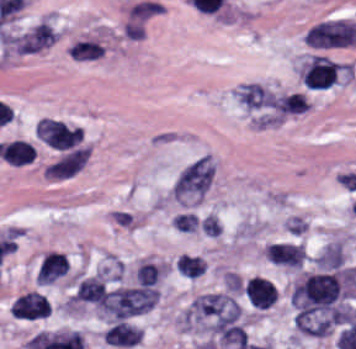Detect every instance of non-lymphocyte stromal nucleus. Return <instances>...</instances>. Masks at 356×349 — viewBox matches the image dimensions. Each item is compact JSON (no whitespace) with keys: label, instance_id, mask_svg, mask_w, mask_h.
Segmentation results:
<instances>
[{"label":"non-lymphocyte stromal nucleus","instance_id":"616ff342","mask_svg":"<svg viewBox=\"0 0 356 349\" xmlns=\"http://www.w3.org/2000/svg\"><path fill=\"white\" fill-rule=\"evenodd\" d=\"M305 257L301 245L271 244L266 250V258L278 266L300 268Z\"/></svg>","mask_w":356,"mask_h":349},{"label":"non-lymphocyte stromal nucleus","instance_id":"51effc4e","mask_svg":"<svg viewBox=\"0 0 356 349\" xmlns=\"http://www.w3.org/2000/svg\"><path fill=\"white\" fill-rule=\"evenodd\" d=\"M104 48L93 40H79L73 43L68 52L74 60H94L102 55Z\"/></svg>","mask_w":356,"mask_h":349},{"label":"non-lymphocyte stromal nucleus","instance_id":"9d01c50a","mask_svg":"<svg viewBox=\"0 0 356 349\" xmlns=\"http://www.w3.org/2000/svg\"><path fill=\"white\" fill-rule=\"evenodd\" d=\"M88 157L87 147H73L49 165V177L70 176L85 164Z\"/></svg>","mask_w":356,"mask_h":349},{"label":"non-lymphocyte stromal nucleus","instance_id":"81446118","mask_svg":"<svg viewBox=\"0 0 356 349\" xmlns=\"http://www.w3.org/2000/svg\"><path fill=\"white\" fill-rule=\"evenodd\" d=\"M356 39V22L344 19L325 20L312 26L304 35V42L316 47L353 44Z\"/></svg>","mask_w":356,"mask_h":349},{"label":"non-lymphocyte stromal nucleus","instance_id":"0ceb972a","mask_svg":"<svg viewBox=\"0 0 356 349\" xmlns=\"http://www.w3.org/2000/svg\"><path fill=\"white\" fill-rule=\"evenodd\" d=\"M309 101L304 93H291L274 98V109L282 114H303L306 112Z\"/></svg>","mask_w":356,"mask_h":349},{"label":"non-lymphocyte stromal nucleus","instance_id":"2ac0efb1","mask_svg":"<svg viewBox=\"0 0 356 349\" xmlns=\"http://www.w3.org/2000/svg\"><path fill=\"white\" fill-rule=\"evenodd\" d=\"M57 33L42 20L18 40V51L35 52L56 41Z\"/></svg>","mask_w":356,"mask_h":349},{"label":"non-lymphocyte stromal nucleus","instance_id":"bbfbcbc0","mask_svg":"<svg viewBox=\"0 0 356 349\" xmlns=\"http://www.w3.org/2000/svg\"><path fill=\"white\" fill-rule=\"evenodd\" d=\"M162 267L148 262H141L136 267L135 277L137 283L147 286L155 285L161 276Z\"/></svg>","mask_w":356,"mask_h":349},{"label":"non-lymphocyte stromal nucleus","instance_id":"3746e769","mask_svg":"<svg viewBox=\"0 0 356 349\" xmlns=\"http://www.w3.org/2000/svg\"><path fill=\"white\" fill-rule=\"evenodd\" d=\"M157 292L145 286L118 287L106 297L100 311L114 319H124L146 311L156 303Z\"/></svg>","mask_w":356,"mask_h":349},{"label":"non-lymphocyte stromal nucleus","instance_id":"a72fc3eb","mask_svg":"<svg viewBox=\"0 0 356 349\" xmlns=\"http://www.w3.org/2000/svg\"><path fill=\"white\" fill-rule=\"evenodd\" d=\"M240 306L227 293H208L195 299L181 315L183 327L220 328L238 321Z\"/></svg>","mask_w":356,"mask_h":349},{"label":"non-lymphocyte stromal nucleus","instance_id":"7c5642bf","mask_svg":"<svg viewBox=\"0 0 356 349\" xmlns=\"http://www.w3.org/2000/svg\"><path fill=\"white\" fill-rule=\"evenodd\" d=\"M35 132L36 136L46 144L65 150L77 145L83 138L79 127L50 118H42L38 121Z\"/></svg>","mask_w":356,"mask_h":349},{"label":"non-lymphocyte stromal nucleus","instance_id":"6412c185","mask_svg":"<svg viewBox=\"0 0 356 349\" xmlns=\"http://www.w3.org/2000/svg\"><path fill=\"white\" fill-rule=\"evenodd\" d=\"M237 98L248 109L270 107L273 103V94L257 83H244Z\"/></svg>","mask_w":356,"mask_h":349},{"label":"non-lymphocyte stromal nucleus","instance_id":"fc2b8d12","mask_svg":"<svg viewBox=\"0 0 356 349\" xmlns=\"http://www.w3.org/2000/svg\"><path fill=\"white\" fill-rule=\"evenodd\" d=\"M213 173L210 157H200L178 173L173 185V197L186 202L201 198L212 182Z\"/></svg>","mask_w":356,"mask_h":349},{"label":"non-lymphocyte stromal nucleus","instance_id":"dd21d789","mask_svg":"<svg viewBox=\"0 0 356 349\" xmlns=\"http://www.w3.org/2000/svg\"><path fill=\"white\" fill-rule=\"evenodd\" d=\"M341 291V278L337 271L305 272L295 281L290 295L301 319L336 305Z\"/></svg>","mask_w":356,"mask_h":349}]
</instances>
